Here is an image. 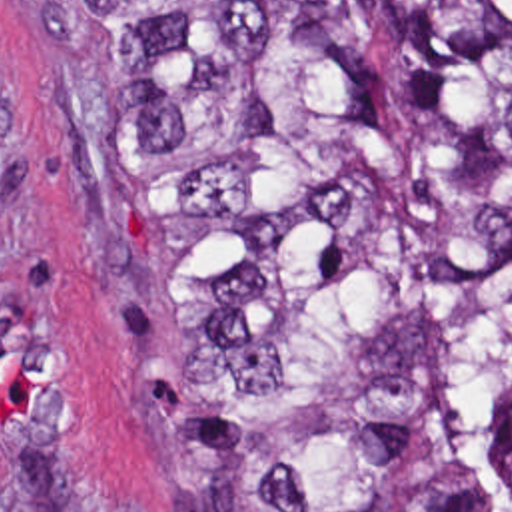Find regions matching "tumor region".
Wrapping results in <instances>:
<instances>
[{
	"instance_id": "tumor-region-1",
	"label": "tumor region",
	"mask_w": 512,
	"mask_h": 512,
	"mask_svg": "<svg viewBox=\"0 0 512 512\" xmlns=\"http://www.w3.org/2000/svg\"><path fill=\"white\" fill-rule=\"evenodd\" d=\"M192 343L184 512H512V0H39Z\"/></svg>"
}]
</instances>
